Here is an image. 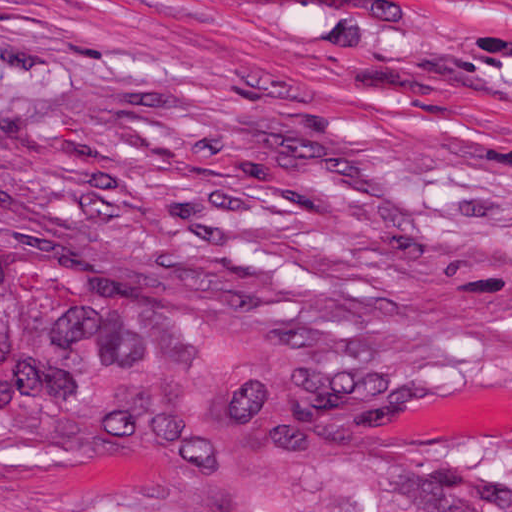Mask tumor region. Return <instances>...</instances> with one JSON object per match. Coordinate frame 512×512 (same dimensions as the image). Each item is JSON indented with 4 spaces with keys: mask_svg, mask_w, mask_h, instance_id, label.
<instances>
[{
    "mask_svg": "<svg viewBox=\"0 0 512 512\" xmlns=\"http://www.w3.org/2000/svg\"><path fill=\"white\" fill-rule=\"evenodd\" d=\"M1 426L159 453L203 512H512L285 319L187 283L1 261Z\"/></svg>",
    "mask_w": 512,
    "mask_h": 512,
    "instance_id": "tumor-region-1",
    "label": "tumor region"
}]
</instances>
